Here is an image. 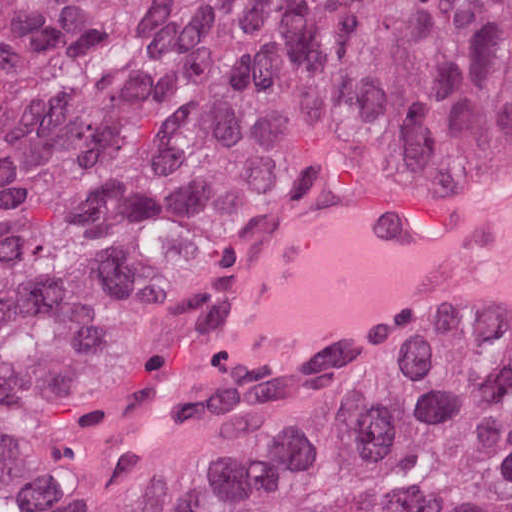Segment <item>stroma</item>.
<instances>
[{
  "mask_svg": "<svg viewBox=\"0 0 512 512\" xmlns=\"http://www.w3.org/2000/svg\"><path fill=\"white\" fill-rule=\"evenodd\" d=\"M512 222V188L462 212L397 216L357 204H332L300 222L251 269L218 324L231 347L255 358L298 361L336 346L385 349L393 358L476 334L512 341L506 329H354L304 349L261 355L266 291L293 274L359 249L415 241Z\"/></svg>",
  "mask_w": 512,
  "mask_h": 512,
  "instance_id": "35a3bbf8",
  "label": "stroma"
}]
</instances>
